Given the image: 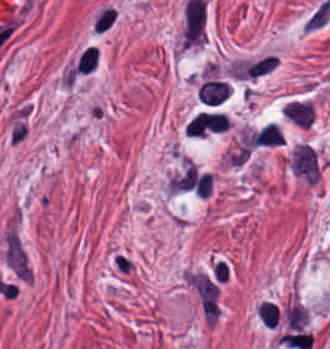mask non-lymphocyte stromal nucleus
<instances>
[{
  "label": "non-lymphocyte stromal nucleus",
  "instance_id": "obj_1",
  "mask_svg": "<svg viewBox=\"0 0 330 349\" xmlns=\"http://www.w3.org/2000/svg\"><path fill=\"white\" fill-rule=\"evenodd\" d=\"M207 3L185 1L180 30V44L185 48L199 47L206 40Z\"/></svg>",
  "mask_w": 330,
  "mask_h": 349
},
{
  "label": "non-lymphocyte stromal nucleus",
  "instance_id": "obj_2",
  "mask_svg": "<svg viewBox=\"0 0 330 349\" xmlns=\"http://www.w3.org/2000/svg\"><path fill=\"white\" fill-rule=\"evenodd\" d=\"M291 174L307 184L320 178L316 151L305 142H298L289 163Z\"/></svg>",
  "mask_w": 330,
  "mask_h": 349
},
{
  "label": "non-lymphocyte stromal nucleus",
  "instance_id": "obj_3",
  "mask_svg": "<svg viewBox=\"0 0 330 349\" xmlns=\"http://www.w3.org/2000/svg\"><path fill=\"white\" fill-rule=\"evenodd\" d=\"M5 258L16 274L31 281L25 256L15 235L10 230L5 233Z\"/></svg>",
  "mask_w": 330,
  "mask_h": 349
},
{
  "label": "non-lymphocyte stromal nucleus",
  "instance_id": "obj_4",
  "mask_svg": "<svg viewBox=\"0 0 330 349\" xmlns=\"http://www.w3.org/2000/svg\"><path fill=\"white\" fill-rule=\"evenodd\" d=\"M284 116L295 125L307 128L313 121V104L307 100L291 99L285 103Z\"/></svg>",
  "mask_w": 330,
  "mask_h": 349
}]
</instances>
